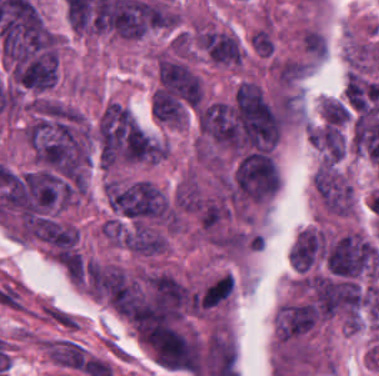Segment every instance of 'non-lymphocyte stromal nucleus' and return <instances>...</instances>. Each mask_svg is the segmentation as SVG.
Masks as SVG:
<instances>
[{
  "label": "non-lymphocyte stromal nucleus",
  "instance_id": "dd21d789",
  "mask_svg": "<svg viewBox=\"0 0 379 376\" xmlns=\"http://www.w3.org/2000/svg\"><path fill=\"white\" fill-rule=\"evenodd\" d=\"M39 308L46 320L64 330H78L79 321L74 314L48 301L39 304Z\"/></svg>",
  "mask_w": 379,
  "mask_h": 376
}]
</instances>
